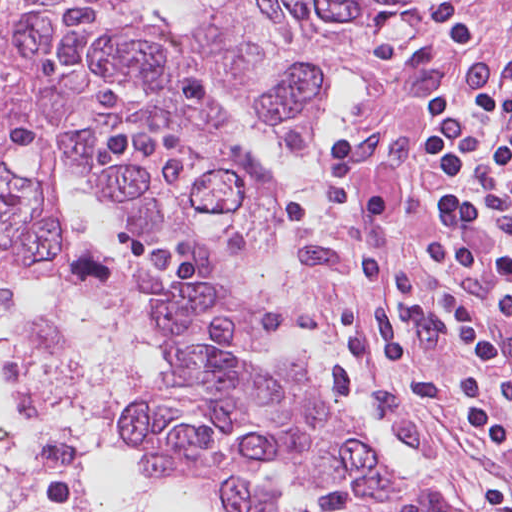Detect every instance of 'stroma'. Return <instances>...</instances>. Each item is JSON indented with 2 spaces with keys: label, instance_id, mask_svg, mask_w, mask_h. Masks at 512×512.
Returning <instances> with one entry per match:
<instances>
[{
  "label": "stroma",
  "instance_id": "35a3bbf8",
  "mask_svg": "<svg viewBox=\"0 0 512 512\" xmlns=\"http://www.w3.org/2000/svg\"><path fill=\"white\" fill-rule=\"evenodd\" d=\"M221 154L239 213L204 268L259 322L221 344L308 368L402 466L403 512H512V0L395 7L317 115ZM79 191L116 214L162 364L179 346L147 323L132 236ZM72 249L69 226L58 257L0 268L53 281Z\"/></svg>",
  "mask_w": 512,
  "mask_h": 512
}]
</instances>
